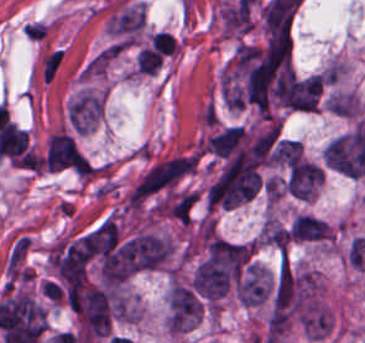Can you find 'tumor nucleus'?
<instances>
[{"label": "tumor nucleus", "instance_id": "tumor-nucleus-1", "mask_svg": "<svg viewBox=\"0 0 365 343\" xmlns=\"http://www.w3.org/2000/svg\"><path fill=\"white\" fill-rule=\"evenodd\" d=\"M203 303L186 284L174 282L170 287L166 324L172 333H186L199 322Z\"/></svg>", "mask_w": 365, "mask_h": 343}, {"label": "tumor nucleus", "instance_id": "tumor-nucleus-2", "mask_svg": "<svg viewBox=\"0 0 365 343\" xmlns=\"http://www.w3.org/2000/svg\"><path fill=\"white\" fill-rule=\"evenodd\" d=\"M323 176L322 170L315 164L300 159L288 171L285 182L288 194L300 200H312Z\"/></svg>", "mask_w": 365, "mask_h": 343}, {"label": "tumor nucleus", "instance_id": "tumor-nucleus-3", "mask_svg": "<svg viewBox=\"0 0 365 343\" xmlns=\"http://www.w3.org/2000/svg\"><path fill=\"white\" fill-rule=\"evenodd\" d=\"M102 105L95 95L83 92L73 100L68 110V121L75 132H88L98 121Z\"/></svg>", "mask_w": 365, "mask_h": 343}, {"label": "tumor nucleus", "instance_id": "tumor-nucleus-4", "mask_svg": "<svg viewBox=\"0 0 365 343\" xmlns=\"http://www.w3.org/2000/svg\"><path fill=\"white\" fill-rule=\"evenodd\" d=\"M300 155L301 147L297 139L280 138L273 152V161L290 166L299 161Z\"/></svg>", "mask_w": 365, "mask_h": 343}]
</instances>
